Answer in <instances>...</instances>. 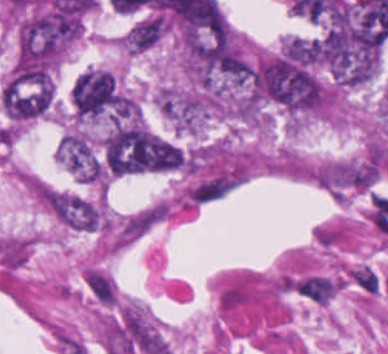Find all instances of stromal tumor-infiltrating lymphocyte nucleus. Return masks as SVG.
Listing matches in <instances>:
<instances>
[{"label":"stromal tumor-infiltrating lymphocyte nucleus","mask_w":388,"mask_h":354,"mask_svg":"<svg viewBox=\"0 0 388 354\" xmlns=\"http://www.w3.org/2000/svg\"><path fill=\"white\" fill-rule=\"evenodd\" d=\"M295 289L318 303H326L336 291V283L326 275H306L295 282Z\"/></svg>","instance_id":"bc302bb0"},{"label":"stromal tumor-infiltrating lymphocyte nucleus","mask_w":388,"mask_h":354,"mask_svg":"<svg viewBox=\"0 0 388 354\" xmlns=\"http://www.w3.org/2000/svg\"><path fill=\"white\" fill-rule=\"evenodd\" d=\"M349 278L366 294H375L380 284V277L369 265H355L349 272Z\"/></svg>","instance_id":"52c7bb5b"}]
</instances>
